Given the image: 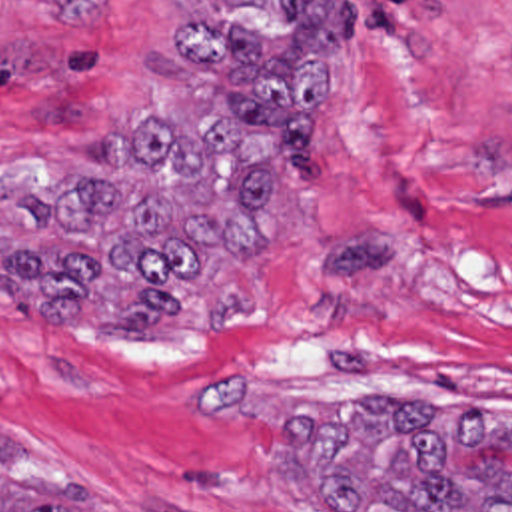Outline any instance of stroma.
<instances>
[{
    "mask_svg": "<svg viewBox=\"0 0 512 512\" xmlns=\"http://www.w3.org/2000/svg\"><path fill=\"white\" fill-rule=\"evenodd\" d=\"M211 0H0V248L23 200L107 174L189 110L175 22ZM317 166L265 200L273 248L177 322H45L0 284V427L53 451L65 512H323L279 445L363 395L512 417V0H345ZM462 473L512 475V445Z\"/></svg>",
    "mask_w": 512,
    "mask_h": 512,
    "instance_id": "stroma-1",
    "label": "stroma"
}]
</instances>
